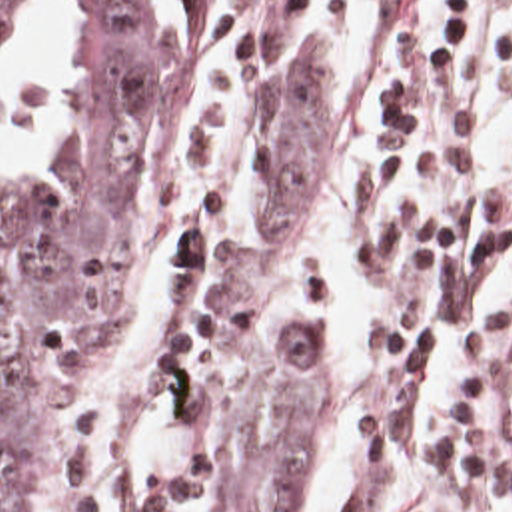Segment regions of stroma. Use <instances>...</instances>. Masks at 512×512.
Instances as JSON below:
<instances>
[{"label": "stroma", "instance_id": "obj_1", "mask_svg": "<svg viewBox=\"0 0 512 512\" xmlns=\"http://www.w3.org/2000/svg\"><path fill=\"white\" fill-rule=\"evenodd\" d=\"M221 48L193 134V178L209 204L177 248V308L171 338L173 399L183 455L153 475L131 473L101 431L97 374L115 348L131 280L153 222L159 166L169 148L187 66L207 44ZM315 50V0H181L173 66L151 122V154L125 232V264L113 280L95 350L67 403V512H235L227 487L233 387L205 332L215 284L237 268L267 200V108L285 62Z\"/></svg>", "mask_w": 512, "mask_h": 512}]
</instances>
